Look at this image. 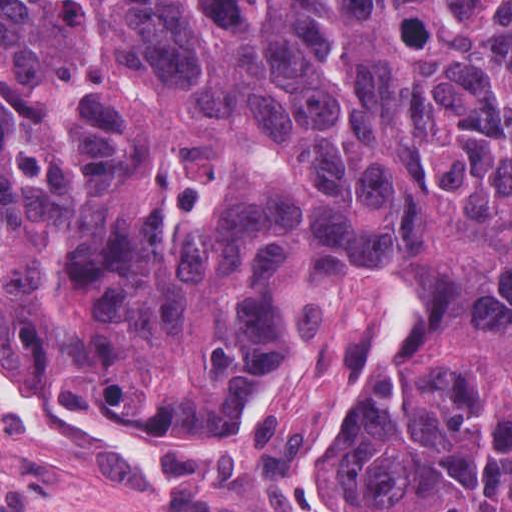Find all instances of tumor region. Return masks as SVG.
<instances>
[{
	"instance_id": "tumor-region-1",
	"label": "tumor region",
	"mask_w": 512,
	"mask_h": 512,
	"mask_svg": "<svg viewBox=\"0 0 512 512\" xmlns=\"http://www.w3.org/2000/svg\"><path fill=\"white\" fill-rule=\"evenodd\" d=\"M346 253L406 272L316 431L373 512H512V0H1V349L236 438Z\"/></svg>"
}]
</instances>
